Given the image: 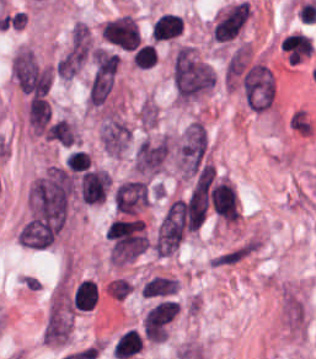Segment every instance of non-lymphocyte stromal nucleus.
Returning a JSON list of instances; mask_svg holds the SVG:
<instances>
[{
	"mask_svg": "<svg viewBox=\"0 0 316 359\" xmlns=\"http://www.w3.org/2000/svg\"><path fill=\"white\" fill-rule=\"evenodd\" d=\"M170 80L175 101L183 105L215 86L211 64L187 45L173 55Z\"/></svg>",
	"mask_w": 316,
	"mask_h": 359,
	"instance_id": "dd21d789",
	"label": "non-lymphocyte stromal nucleus"
},
{
	"mask_svg": "<svg viewBox=\"0 0 316 359\" xmlns=\"http://www.w3.org/2000/svg\"><path fill=\"white\" fill-rule=\"evenodd\" d=\"M251 15L248 1L230 6L216 22L213 33L217 41H231L238 36Z\"/></svg>",
	"mask_w": 316,
	"mask_h": 359,
	"instance_id": "6412c185",
	"label": "non-lymphocyte stromal nucleus"
},
{
	"mask_svg": "<svg viewBox=\"0 0 316 359\" xmlns=\"http://www.w3.org/2000/svg\"><path fill=\"white\" fill-rule=\"evenodd\" d=\"M150 196V184L142 176L120 180L113 193L112 204L119 216H138Z\"/></svg>",
	"mask_w": 316,
	"mask_h": 359,
	"instance_id": "7c5642bf",
	"label": "non-lymphocyte stromal nucleus"
},
{
	"mask_svg": "<svg viewBox=\"0 0 316 359\" xmlns=\"http://www.w3.org/2000/svg\"><path fill=\"white\" fill-rule=\"evenodd\" d=\"M242 93L254 112L269 108L274 101V79L269 68L261 64L250 67L242 79Z\"/></svg>",
	"mask_w": 316,
	"mask_h": 359,
	"instance_id": "81446118",
	"label": "non-lymphocyte stromal nucleus"
},
{
	"mask_svg": "<svg viewBox=\"0 0 316 359\" xmlns=\"http://www.w3.org/2000/svg\"><path fill=\"white\" fill-rule=\"evenodd\" d=\"M94 48L92 34L84 21H77L58 57V78H73L90 59Z\"/></svg>",
	"mask_w": 316,
	"mask_h": 359,
	"instance_id": "fc2b8d12",
	"label": "non-lymphocyte stromal nucleus"
},
{
	"mask_svg": "<svg viewBox=\"0 0 316 359\" xmlns=\"http://www.w3.org/2000/svg\"><path fill=\"white\" fill-rule=\"evenodd\" d=\"M169 153L168 136L143 141L135 152L133 170L137 174H154L162 168Z\"/></svg>",
	"mask_w": 316,
	"mask_h": 359,
	"instance_id": "9d01c50a",
	"label": "non-lymphocyte stromal nucleus"
},
{
	"mask_svg": "<svg viewBox=\"0 0 316 359\" xmlns=\"http://www.w3.org/2000/svg\"><path fill=\"white\" fill-rule=\"evenodd\" d=\"M173 153L180 176L194 177L211 164L207 129L191 121L173 137Z\"/></svg>",
	"mask_w": 316,
	"mask_h": 359,
	"instance_id": "3746e769",
	"label": "non-lymphocyte stromal nucleus"
},
{
	"mask_svg": "<svg viewBox=\"0 0 316 359\" xmlns=\"http://www.w3.org/2000/svg\"><path fill=\"white\" fill-rule=\"evenodd\" d=\"M101 36L105 41L125 49H136L141 43L137 22L133 16L126 14L106 20Z\"/></svg>",
	"mask_w": 316,
	"mask_h": 359,
	"instance_id": "2ac0efb1",
	"label": "non-lymphocyte stromal nucleus"
},
{
	"mask_svg": "<svg viewBox=\"0 0 316 359\" xmlns=\"http://www.w3.org/2000/svg\"><path fill=\"white\" fill-rule=\"evenodd\" d=\"M26 112L31 127L37 131H44L51 116L49 104L29 100Z\"/></svg>",
	"mask_w": 316,
	"mask_h": 359,
	"instance_id": "51effc4e",
	"label": "non-lymphocyte stromal nucleus"
},
{
	"mask_svg": "<svg viewBox=\"0 0 316 359\" xmlns=\"http://www.w3.org/2000/svg\"><path fill=\"white\" fill-rule=\"evenodd\" d=\"M46 138L66 149H73L79 142L75 126L62 116H55L46 126Z\"/></svg>",
	"mask_w": 316,
	"mask_h": 359,
	"instance_id": "0ceb972a",
	"label": "non-lymphocyte stromal nucleus"
},
{
	"mask_svg": "<svg viewBox=\"0 0 316 359\" xmlns=\"http://www.w3.org/2000/svg\"><path fill=\"white\" fill-rule=\"evenodd\" d=\"M131 138L129 125L118 115H105L99 129L101 147L112 155H121Z\"/></svg>",
	"mask_w": 316,
	"mask_h": 359,
	"instance_id": "616ff342",
	"label": "non-lymphocyte stromal nucleus"
},
{
	"mask_svg": "<svg viewBox=\"0 0 316 359\" xmlns=\"http://www.w3.org/2000/svg\"><path fill=\"white\" fill-rule=\"evenodd\" d=\"M141 308L146 329L167 326L180 311L177 280L165 275L149 276L141 289Z\"/></svg>",
	"mask_w": 316,
	"mask_h": 359,
	"instance_id": "a72fc3eb",
	"label": "non-lymphocyte stromal nucleus"
}]
</instances>
